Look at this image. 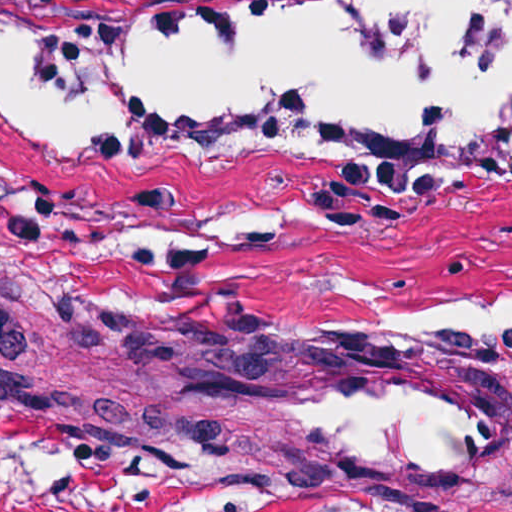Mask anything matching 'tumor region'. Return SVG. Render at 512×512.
<instances>
[{
	"mask_svg": "<svg viewBox=\"0 0 512 512\" xmlns=\"http://www.w3.org/2000/svg\"><path fill=\"white\" fill-rule=\"evenodd\" d=\"M0 296L15 299V300L35 303V304H41V305H46V306H51V307L72 310V311H76V312H80V313H84V314H89V315L105 318L107 320H110L112 322L118 323L123 326H142V325L133 323L131 321L125 320L123 318H120L118 316L112 315L110 313H107L105 311L99 310L97 308L68 302V301L62 300L60 298L45 294L43 292L31 289V288L13 286V285H7V284L0 283ZM121 452H124L127 454H140V453L126 452V451H121ZM185 461L191 462L193 464H199L194 461H189V460H185ZM299 484H303V483H299ZM362 512H368V511H366L364 508H362Z\"/></svg>",
	"mask_w": 512,
	"mask_h": 512,
	"instance_id": "1",
	"label": "tumor region"
}]
</instances>
